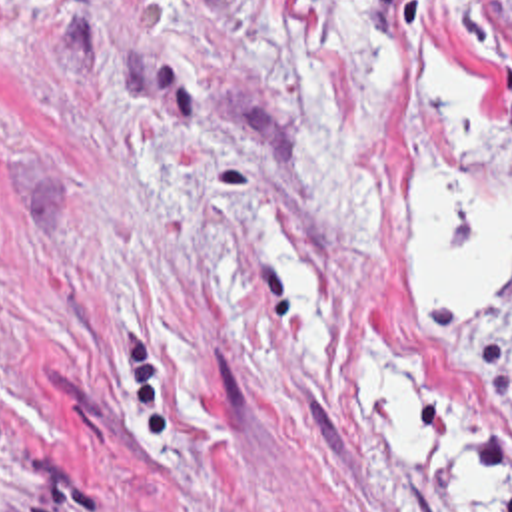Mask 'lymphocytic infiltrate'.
<instances>
[{
    "instance_id": "obj_1",
    "label": "lymphocytic infiltrate",
    "mask_w": 512,
    "mask_h": 512,
    "mask_svg": "<svg viewBox=\"0 0 512 512\" xmlns=\"http://www.w3.org/2000/svg\"><path fill=\"white\" fill-rule=\"evenodd\" d=\"M454 20L466 38L486 42L506 30V0H428ZM502 94L512 110V72L500 78Z\"/></svg>"
}]
</instances>
